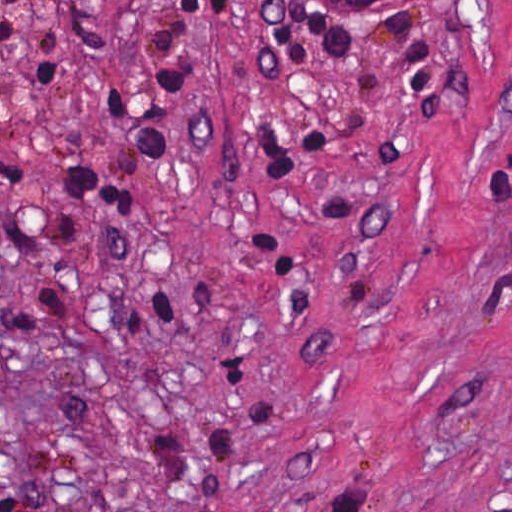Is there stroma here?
I'll list each match as a JSON object with an SVG mask.
<instances>
[{"mask_svg":"<svg viewBox=\"0 0 512 512\" xmlns=\"http://www.w3.org/2000/svg\"><path fill=\"white\" fill-rule=\"evenodd\" d=\"M14 2L0 154L55 234L0 223V497L512 512V0H203L190 126L127 225L71 164L138 0H74L37 91Z\"/></svg>","mask_w":512,"mask_h":512,"instance_id":"obj_1","label":"stroma"}]
</instances>
